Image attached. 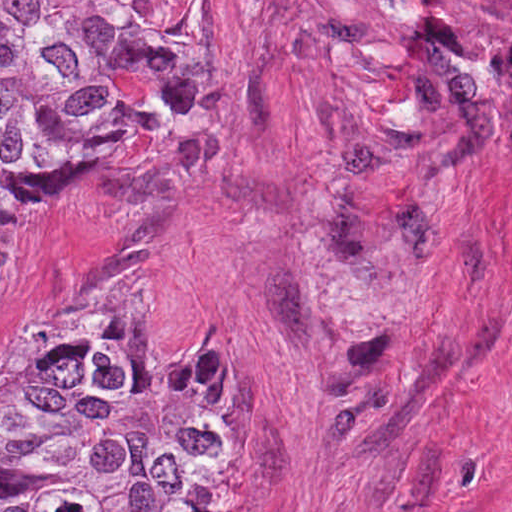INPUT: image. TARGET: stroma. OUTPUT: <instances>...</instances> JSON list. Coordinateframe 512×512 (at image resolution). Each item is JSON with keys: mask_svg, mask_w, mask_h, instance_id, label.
Returning <instances> with one entry per match:
<instances>
[{"mask_svg": "<svg viewBox=\"0 0 512 512\" xmlns=\"http://www.w3.org/2000/svg\"><path fill=\"white\" fill-rule=\"evenodd\" d=\"M0 1H162L210 58L14 236L0 374L100 285L154 355L230 346L224 512H512V0Z\"/></svg>", "mask_w": 512, "mask_h": 512, "instance_id": "1", "label": "stroma"}]
</instances>
